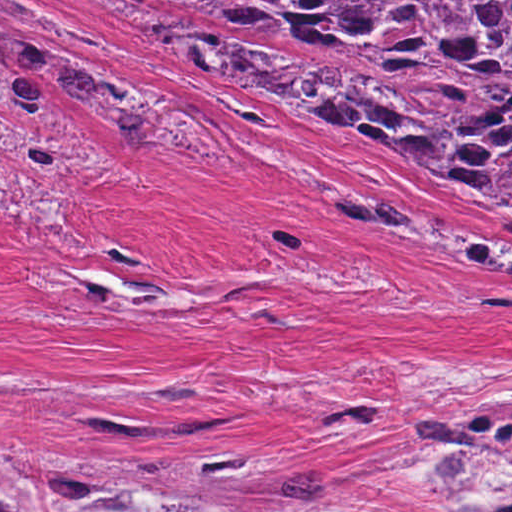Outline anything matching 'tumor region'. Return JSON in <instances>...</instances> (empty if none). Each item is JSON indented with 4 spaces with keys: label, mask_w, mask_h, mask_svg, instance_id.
<instances>
[{
    "label": "tumor region",
    "mask_w": 512,
    "mask_h": 512,
    "mask_svg": "<svg viewBox=\"0 0 512 512\" xmlns=\"http://www.w3.org/2000/svg\"><path fill=\"white\" fill-rule=\"evenodd\" d=\"M198 8L349 36L378 52L394 90L338 59L280 51L242 31L191 43L151 20L149 42L167 69L270 73L379 141L394 143L512 199V0H181ZM0 8L46 22L14 0ZM21 50L81 119L115 138H153L149 112L70 56L55 40L0 15V49ZM61 114L40 87L0 64V105ZM243 149L246 140L238 138ZM105 434H198L231 422H147L86 415ZM362 432L378 408L340 412ZM465 512H512V378L463 398L416 440ZM311 445L308 424L255 432L191 471L123 451L0 444V512H256ZM291 483L266 512H298L315 498V473Z\"/></svg>",
    "instance_id": "1"
}]
</instances>
